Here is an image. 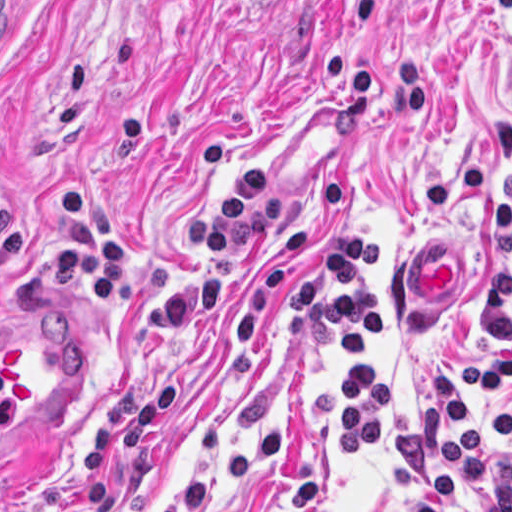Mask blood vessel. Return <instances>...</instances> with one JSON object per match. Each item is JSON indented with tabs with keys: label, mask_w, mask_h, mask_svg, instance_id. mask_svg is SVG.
<instances>
[{
	"label": "blood vessel",
	"mask_w": 512,
	"mask_h": 512,
	"mask_svg": "<svg viewBox=\"0 0 512 512\" xmlns=\"http://www.w3.org/2000/svg\"><path fill=\"white\" fill-rule=\"evenodd\" d=\"M12 0H0V19ZM416 241L405 266V293L418 317H436L463 293V254ZM0 347V482L39 455L80 399V366L56 328H24Z\"/></svg>",
	"instance_id": "obj_1"
}]
</instances>
